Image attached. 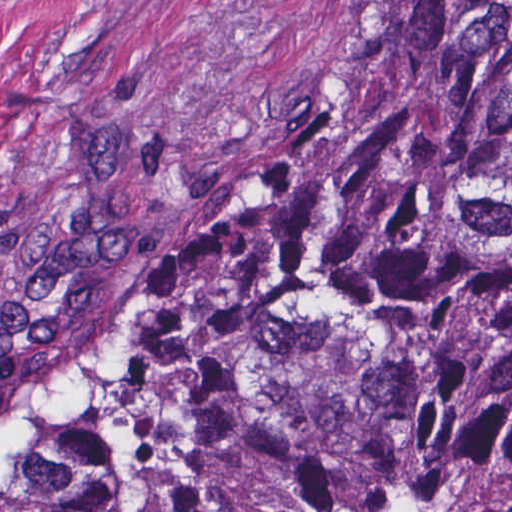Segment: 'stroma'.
I'll return each mask as SVG.
<instances>
[{
    "label": "stroma",
    "mask_w": 512,
    "mask_h": 512,
    "mask_svg": "<svg viewBox=\"0 0 512 512\" xmlns=\"http://www.w3.org/2000/svg\"><path fill=\"white\" fill-rule=\"evenodd\" d=\"M384 1L0 0V478L131 360L175 249Z\"/></svg>",
    "instance_id": "stroma-1"
}]
</instances>
